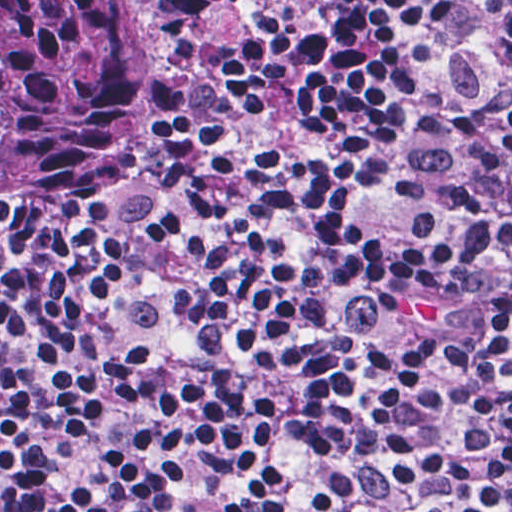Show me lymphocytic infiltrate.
I'll list each match as a JSON object with an SVG mask.
<instances>
[{"label": "lymphocytic infiltrate", "mask_w": 512, "mask_h": 512, "mask_svg": "<svg viewBox=\"0 0 512 512\" xmlns=\"http://www.w3.org/2000/svg\"><path fill=\"white\" fill-rule=\"evenodd\" d=\"M140 2L109 158L0 237V512H512V0Z\"/></svg>", "instance_id": "lymphocytic-infiltrate-1"}]
</instances>
